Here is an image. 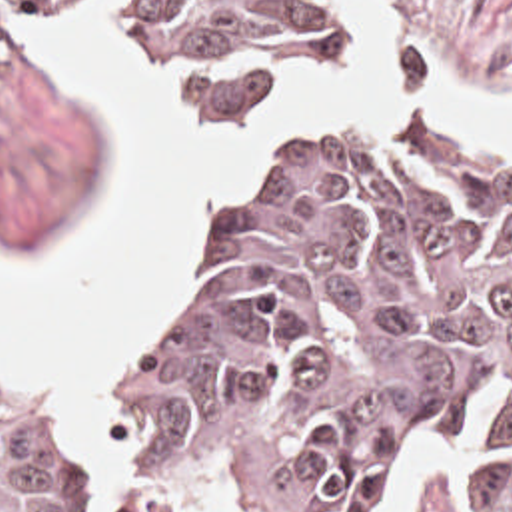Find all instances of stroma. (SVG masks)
<instances>
[{
	"label": "stroma",
	"mask_w": 512,
	"mask_h": 512,
	"mask_svg": "<svg viewBox=\"0 0 512 512\" xmlns=\"http://www.w3.org/2000/svg\"><path fill=\"white\" fill-rule=\"evenodd\" d=\"M11 2V42L0 48V242L13 248H47L67 240L77 220L101 190L107 158L105 124L91 102L49 76L27 40V20L45 12L31 0ZM389 28V56L405 94L417 98L427 84L453 82L467 92L512 106V0H375ZM345 4V42L349 36ZM113 38L127 58L165 76L173 100L203 120L251 122L267 108L221 106L203 90L175 78L153 62L123 24L111 18ZM335 64L327 66L333 68ZM411 110H445L473 124L497 150L512 152V136L495 114L471 102L377 100L353 118H321L285 138L265 158L225 176L207 194V212L187 244L171 288L157 314L127 342L115 360L107 390L119 368L139 354L175 314L185 290L199 236L223 184L277 158L305 150L329 136L363 128ZM105 390V394H107ZM0 398L21 420L51 436L73 460L123 478L141 464V438L115 426L107 398V420L125 450L113 462H87L77 454L53 416L43 392L31 386L0 352ZM479 444L455 440L407 450L385 460L371 482V512H463L457 493V462ZM219 499L215 512H233L229 489L195 495L179 512H197Z\"/></svg>",
	"instance_id": "1"
}]
</instances>
